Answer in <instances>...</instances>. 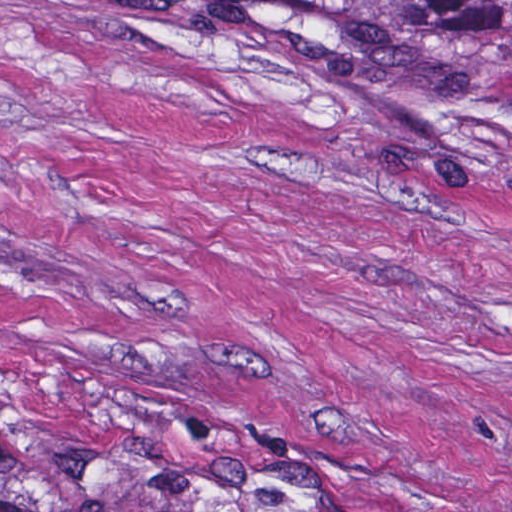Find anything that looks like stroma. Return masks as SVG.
<instances>
[{
	"instance_id": "35a3bbf8",
	"label": "stroma",
	"mask_w": 512,
	"mask_h": 512,
	"mask_svg": "<svg viewBox=\"0 0 512 512\" xmlns=\"http://www.w3.org/2000/svg\"><path fill=\"white\" fill-rule=\"evenodd\" d=\"M0 392L209 511L512 512V69L0 0Z\"/></svg>"
}]
</instances>
